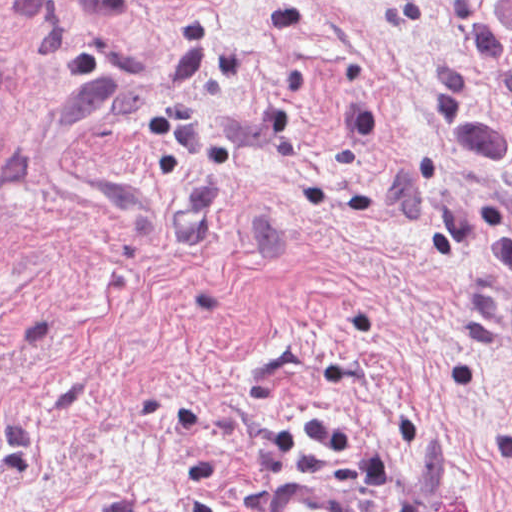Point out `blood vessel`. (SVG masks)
Here are the masks:
<instances>
[{
    "label": "blood vessel",
    "mask_w": 512,
    "mask_h": 512,
    "mask_svg": "<svg viewBox=\"0 0 512 512\" xmlns=\"http://www.w3.org/2000/svg\"><path fill=\"white\" fill-rule=\"evenodd\" d=\"M258 512H357L317 487L290 478H274L258 501Z\"/></svg>",
    "instance_id": "blood-vessel-1"
}]
</instances>
